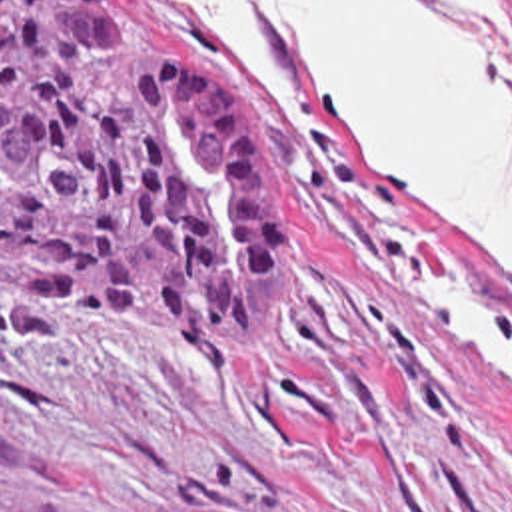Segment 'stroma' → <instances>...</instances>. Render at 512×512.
Masks as SVG:
<instances>
[{
    "label": "stroma",
    "mask_w": 512,
    "mask_h": 512,
    "mask_svg": "<svg viewBox=\"0 0 512 512\" xmlns=\"http://www.w3.org/2000/svg\"><path fill=\"white\" fill-rule=\"evenodd\" d=\"M118 2L238 104L276 210L278 314L262 344L224 358L0 296V499L512 512V382L408 288L446 258L512 320L480 238L388 192L260 10L302 122H276L180 0Z\"/></svg>",
    "instance_id": "stroma-1"
}]
</instances>
